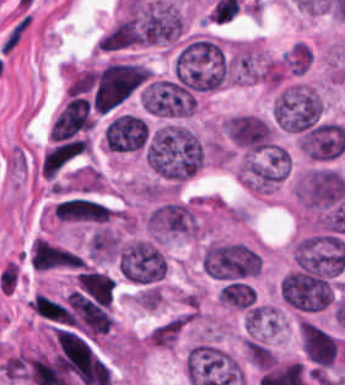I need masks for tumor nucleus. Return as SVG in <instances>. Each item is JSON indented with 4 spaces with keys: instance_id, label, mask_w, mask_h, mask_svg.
Returning a JSON list of instances; mask_svg holds the SVG:
<instances>
[{
    "instance_id": "tumor-nucleus-1",
    "label": "tumor nucleus",
    "mask_w": 345,
    "mask_h": 385,
    "mask_svg": "<svg viewBox=\"0 0 345 385\" xmlns=\"http://www.w3.org/2000/svg\"><path fill=\"white\" fill-rule=\"evenodd\" d=\"M144 158L150 169L179 182L200 169L203 149L198 137L185 126L165 123L150 137Z\"/></svg>"
},
{
    "instance_id": "tumor-nucleus-2",
    "label": "tumor nucleus",
    "mask_w": 345,
    "mask_h": 385,
    "mask_svg": "<svg viewBox=\"0 0 345 385\" xmlns=\"http://www.w3.org/2000/svg\"><path fill=\"white\" fill-rule=\"evenodd\" d=\"M175 80L194 92L209 93L225 86L224 51L220 41L191 34L173 57Z\"/></svg>"
},
{
    "instance_id": "tumor-nucleus-3",
    "label": "tumor nucleus",
    "mask_w": 345,
    "mask_h": 385,
    "mask_svg": "<svg viewBox=\"0 0 345 385\" xmlns=\"http://www.w3.org/2000/svg\"><path fill=\"white\" fill-rule=\"evenodd\" d=\"M205 274L222 281L254 278L262 269V257L249 246L210 241L202 255Z\"/></svg>"
},
{
    "instance_id": "tumor-nucleus-4",
    "label": "tumor nucleus",
    "mask_w": 345,
    "mask_h": 385,
    "mask_svg": "<svg viewBox=\"0 0 345 385\" xmlns=\"http://www.w3.org/2000/svg\"><path fill=\"white\" fill-rule=\"evenodd\" d=\"M321 112L317 91L305 83H291L280 89L272 103L274 123L288 133L317 121Z\"/></svg>"
},
{
    "instance_id": "tumor-nucleus-5",
    "label": "tumor nucleus",
    "mask_w": 345,
    "mask_h": 385,
    "mask_svg": "<svg viewBox=\"0 0 345 385\" xmlns=\"http://www.w3.org/2000/svg\"><path fill=\"white\" fill-rule=\"evenodd\" d=\"M117 263L119 273L129 283L151 284L166 274L162 254L146 240H133L119 246Z\"/></svg>"
},
{
    "instance_id": "tumor-nucleus-6",
    "label": "tumor nucleus",
    "mask_w": 345,
    "mask_h": 385,
    "mask_svg": "<svg viewBox=\"0 0 345 385\" xmlns=\"http://www.w3.org/2000/svg\"><path fill=\"white\" fill-rule=\"evenodd\" d=\"M141 107L151 116L187 118L194 113V96L176 80H150L141 93Z\"/></svg>"
},
{
    "instance_id": "tumor-nucleus-7",
    "label": "tumor nucleus",
    "mask_w": 345,
    "mask_h": 385,
    "mask_svg": "<svg viewBox=\"0 0 345 385\" xmlns=\"http://www.w3.org/2000/svg\"><path fill=\"white\" fill-rule=\"evenodd\" d=\"M221 134L246 158L268 153L269 127L264 117L249 112H236L225 118Z\"/></svg>"
},
{
    "instance_id": "tumor-nucleus-8",
    "label": "tumor nucleus",
    "mask_w": 345,
    "mask_h": 385,
    "mask_svg": "<svg viewBox=\"0 0 345 385\" xmlns=\"http://www.w3.org/2000/svg\"><path fill=\"white\" fill-rule=\"evenodd\" d=\"M279 296L291 308L309 312L332 302L333 286L329 278L286 273L279 283Z\"/></svg>"
},
{
    "instance_id": "tumor-nucleus-9",
    "label": "tumor nucleus",
    "mask_w": 345,
    "mask_h": 385,
    "mask_svg": "<svg viewBox=\"0 0 345 385\" xmlns=\"http://www.w3.org/2000/svg\"><path fill=\"white\" fill-rule=\"evenodd\" d=\"M105 148L111 151H135L146 143V122L130 112L110 120L102 133Z\"/></svg>"
},
{
    "instance_id": "tumor-nucleus-10",
    "label": "tumor nucleus",
    "mask_w": 345,
    "mask_h": 385,
    "mask_svg": "<svg viewBox=\"0 0 345 385\" xmlns=\"http://www.w3.org/2000/svg\"><path fill=\"white\" fill-rule=\"evenodd\" d=\"M144 31L130 13H126L100 34L96 52L120 53L141 46Z\"/></svg>"
},
{
    "instance_id": "tumor-nucleus-11",
    "label": "tumor nucleus",
    "mask_w": 345,
    "mask_h": 385,
    "mask_svg": "<svg viewBox=\"0 0 345 385\" xmlns=\"http://www.w3.org/2000/svg\"><path fill=\"white\" fill-rule=\"evenodd\" d=\"M216 298L232 309L246 310L253 304L255 292L247 282L234 279L221 286Z\"/></svg>"
},
{
    "instance_id": "tumor-nucleus-12",
    "label": "tumor nucleus",
    "mask_w": 345,
    "mask_h": 385,
    "mask_svg": "<svg viewBox=\"0 0 345 385\" xmlns=\"http://www.w3.org/2000/svg\"><path fill=\"white\" fill-rule=\"evenodd\" d=\"M313 58L312 49L303 41H296L280 58L286 74H303Z\"/></svg>"
}]
</instances>
